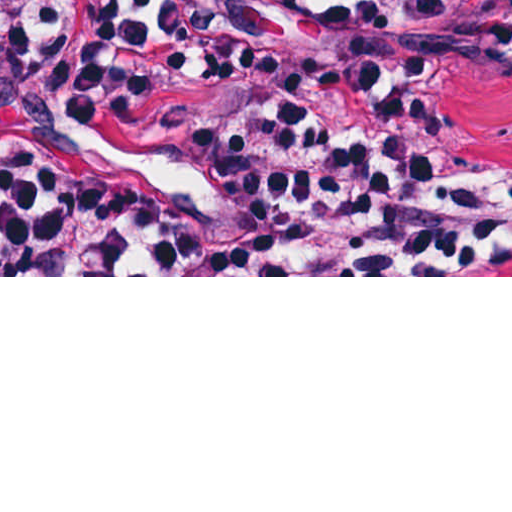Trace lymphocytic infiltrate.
<instances>
[{
	"instance_id": "f902f5d3",
	"label": "lymphocytic infiltrate",
	"mask_w": 512,
	"mask_h": 512,
	"mask_svg": "<svg viewBox=\"0 0 512 512\" xmlns=\"http://www.w3.org/2000/svg\"><path fill=\"white\" fill-rule=\"evenodd\" d=\"M512 59V0H386ZM332 0H129L0 28V120L79 125L0 173V275H495L512 182Z\"/></svg>"
}]
</instances>
